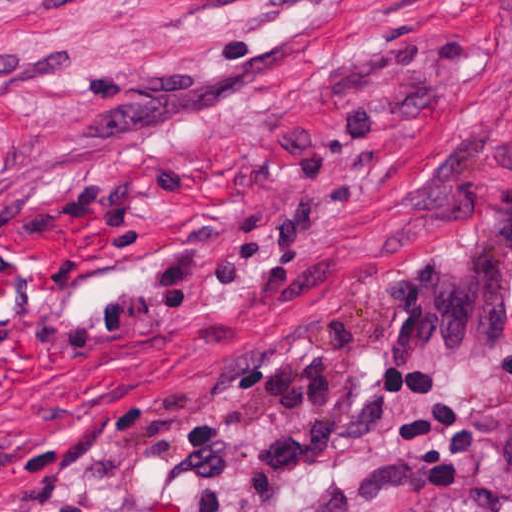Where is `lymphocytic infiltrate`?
I'll list each match as a JSON object with an SVG mask.
<instances>
[{
    "instance_id": "obj_1",
    "label": "lymphocytic infiltrate",
    "mask_w": 512,
    "mask_h": 512,
    "mask_svg": "<svg viewBox=\"0 0 512 512\" xmlns=\"http://www.w3.org/2000/svg\"><path fill=\"white\" fill-rule=\"evenodd\" d=\"M381 109L382 99L370 97L323 116L313 138L295 148L283 199L266 211H195L189 231L133 280L28 340L47 354L77 358L101 337L174 322L220 286L245 295L284 291L286 269L264 266L306 252L357 210L361 178L346 169ZM380 388L400 413L412 482L424 492L450 489L477 460V430L455 393L439 377ZM364 402L345 310L294 324L229 367L218 421L208 413L181 427L155 472L173 490L162 512H312L322 462ZM63 512H89V504Z\"/></svg>"
}]
</instances>
